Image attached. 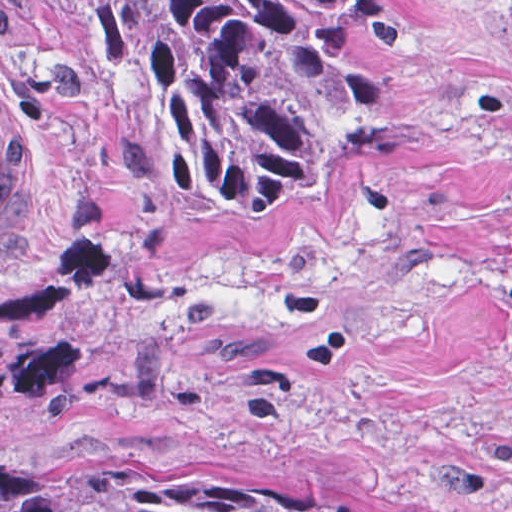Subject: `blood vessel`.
Listing matches in <instances>:
<instances>
[{
    "mask_svg": "<svg viewBox=\"0 0 512 512\" xmlns=\"http://www.w3.org/2000/svg\"><path fill=\"white\" fill-rule=\"evenodd\" d=\"M36 189L37 177L21 137L0 113V256L23 237Z\"/></svg>",
    "mask_w": 512,
    "mask_h": 512,
    "instance_id": "8fb6f2fc",
    "label": "blood vessel"
}]
</instances>
